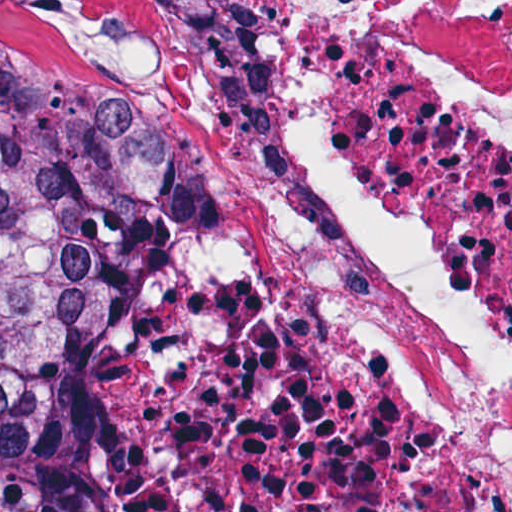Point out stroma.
Returning a JSON list of instances; mask_svg holds the SVG:
<instances>
[{
    "instance_id": "obj_1",
    "label": "stroma",
    "mask_w": 512,
    "mask_h": 512,
    "mask_svg": "<svg viewBox=\"0 0 512 512\" xmlns=\"http://www.w3.org/2000/svg\"><path fill=\"white\" fill-rule=\"evenodd\" d=\"M174 1H512V0H0V23L41 48H107L158 59ZM189 166L174 200L180 198Z\"/></svg>"
}]
</instances>
